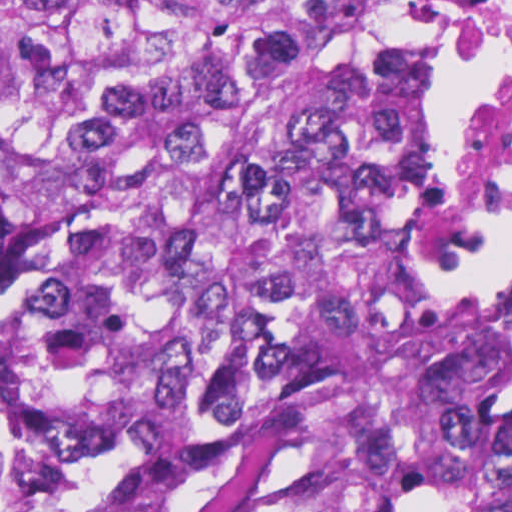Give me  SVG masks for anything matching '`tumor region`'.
Here are the masks:
<instances>
[{"instance_id":"tumor-region-1","label":"tumor region","mask_w":512,"mask_h":512,"mask_svg":"<svg viewBox=\"0 0 512 512\" xmlns=\"http://www.w3.org/2000/svg\"><path fill=\"white\" fill-rule=\"evenodd\" d=\"M481 0H0V512H201L327 341L333 512H512V292L431 289Z\"/></svg>"}]
</instances>
